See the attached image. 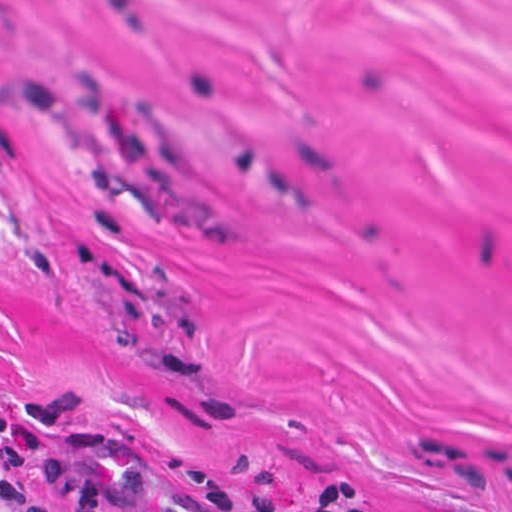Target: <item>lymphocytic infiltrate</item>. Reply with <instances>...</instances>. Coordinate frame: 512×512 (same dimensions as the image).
<instances>
[{"instance_id": "lymphocytic-infiltrate-1", "label": "lymphocytic infiltrate", "mask_w": 512, "mask_h": 512, "mask_svg": "<svg viewBox=\"0 0 512 512\" xmlns=\"http://www.w3.org/2000/svg\"><path fill=\"white\" fill-rule=\"evenodd\" d=\"M355 469L333 474L300 512H385ZM0 512H243L175 445L109 437L0 456Z\"/></svg>"}]
</instances>
